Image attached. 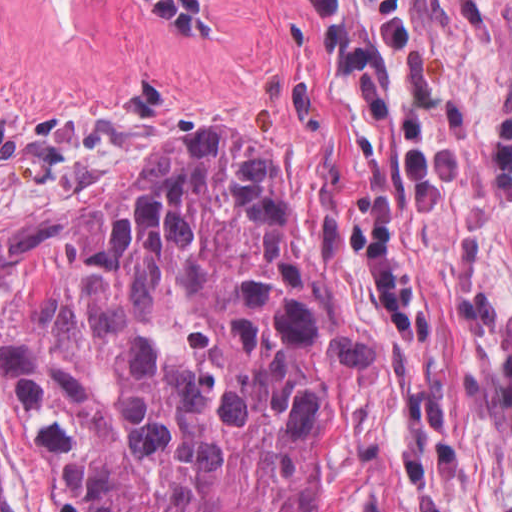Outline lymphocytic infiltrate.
Instances as JSON below:
<instances>
[{"label":"lymphocytic infiltrate","mask_w":512,"mask_h":512,"mask_svg":"<svg viewBox=\"0 0 512 512\" xmlns=\"http://www.w3.org/2000/svg\"><path fill=\"white\" fill-rule=\"evenodd\" d=\"M152 8L177 34H210L204 5L198 0H138ZM316 21V35L357 100L378 123L396 151L406 176L416 213H431L444 205L460 178V151L442 135L429 113L417 108L400 114L378 66L363 43L355 17L345 0H300ZM370 27L381 46L406 52L412 29L403 0H365Z\"/></svg>","instance_id":"lymphocytic-infiltrate-1"}]
</instances>
